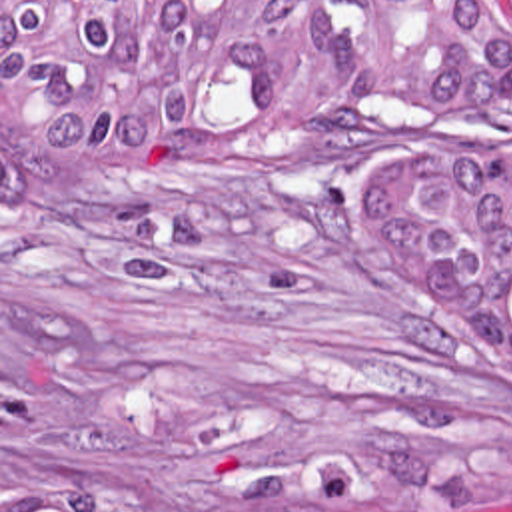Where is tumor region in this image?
<instances>
[{
	"mask_svg": "<svg viewBox=\"0 0 512 512\" xmlns=\"http://www.w3.org/2000/svg\"><path fill=\"white\" fill-rule=\"evenodd\" d=\"M512 40L483 0H2V210L48 174H144L194 140L323 136L371 110L447 132L505 108ZM381 256L473 350L512 422V154L423 144L351 186ZM2 512H218L184 495H36ZM282 512H393L315 461Z\"/></svg>",
	"mask_w": 512,
	"mask_h": 512,
	"instance_id": "tumor-region-1",
	"label": "tumor region"
}]
</instances>
